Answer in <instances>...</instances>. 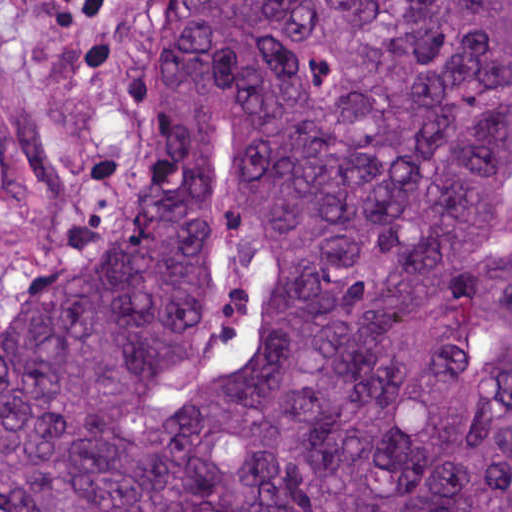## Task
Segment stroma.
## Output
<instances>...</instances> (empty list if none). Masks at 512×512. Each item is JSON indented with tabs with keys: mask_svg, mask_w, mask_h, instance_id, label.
I'll list each match as a JSON object with an SVG mask.
<instances>
[{
	"mask_svg": "<svg viewBox=\"0 0 512 512\" xmlns=\"http://www.w3.org/2000/svg\"><path fill=\"white\" fill-rule=\"evenodd\" d=\"M160 0H0V342L72 274L141 158Z\"/></svg>",
	"mask_w": 512,
	"mask_h": 512,
	"instance_id": "1",
	"label": "stroma"
}]
</instances>
